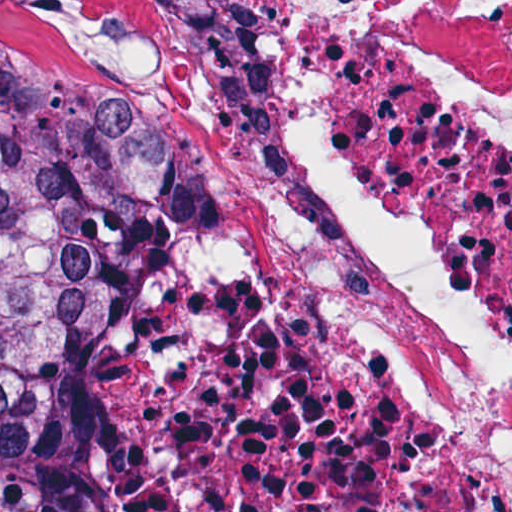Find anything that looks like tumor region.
<instances>
[{"mask_svg": "<svg viewBox=\"0 0 512 512\" xmlns=\"http://www.w3.org/2000/svg\"><path fill=\"white\" fill-rule=\"evenodd\" d=\"M188 166L158 59L0 23V512H67L72 368Z\"/></svg>", "mask_w": 512, "mask_h": 512, "instance_id": "1", "label": "tumor region"}]
</instances>
